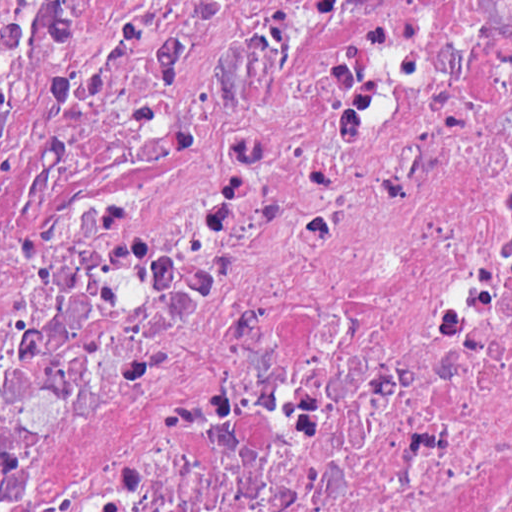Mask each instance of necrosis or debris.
<instances>
[{
  "instance_id": "necrosis-or-debris-1",
  "label": "necrosis or debris",
  "mask_w": 512,
  "mask_h": 512,
  "mask_svg": "<svg viewBox=\"0 0 512 512\" xmlns=\"http://www.w3.org/2000/svg\"><path fill=\"white\" fill-rule=\"evenodd\" d=\"M0 512H512V0H0Z\"/></svg>"
}]
</instances>
